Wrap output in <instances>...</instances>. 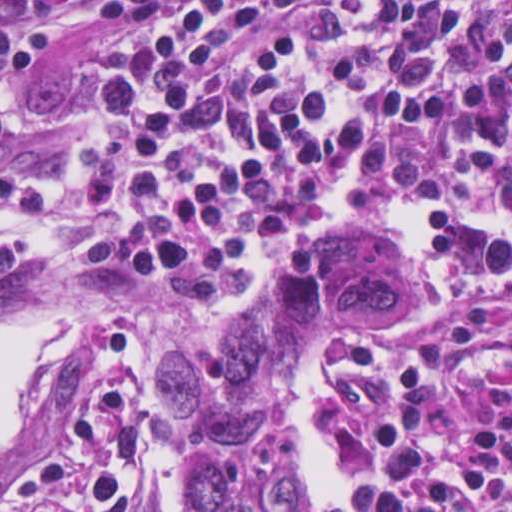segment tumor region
Returning <instances> with one entry per match:
<instances>
[{"mask_svg": "<svg viewBox=\"0 0 512 512\" xmlns=\"http://www.w3.org/2000/svg\"><path fill=\"white\" fill-rule=\"evenodd\" d=\"M423 295L424 278L385 240L316 237L282 262L242 331L181 345L161 400L197 437L179 468L181 512H301L302 470L281 431L304 338Z\"/></svg>", "mask_w": 512, "mask_h": 512, "instance_id": "obj_1", "label": "tumor region"}]
</instances>
